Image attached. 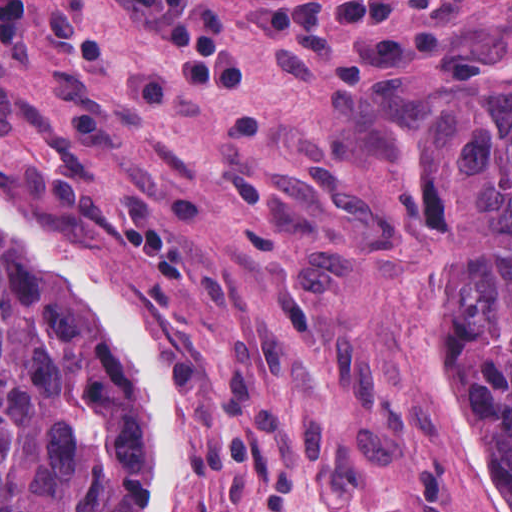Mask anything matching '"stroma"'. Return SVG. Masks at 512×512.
I'll return each mask as SVG.
<instances>
[{
    "instance_id": "1",
    "label": "stroma",
    "mask_w": 512,
    "mask_h": 512,
    "mask_svg": "<svg viewBox=\"0 0 512 512\" xmlns=\"http://www.w3.org/2000/svg\"><path fill=\"white\" fill-rule=\"evenodd\" d=\"M511 73L512 0H0V207L148 336L176 512H485L399 174ZM0 258L137 415L55 279Z\"/></svg>"
}]
</instances>
